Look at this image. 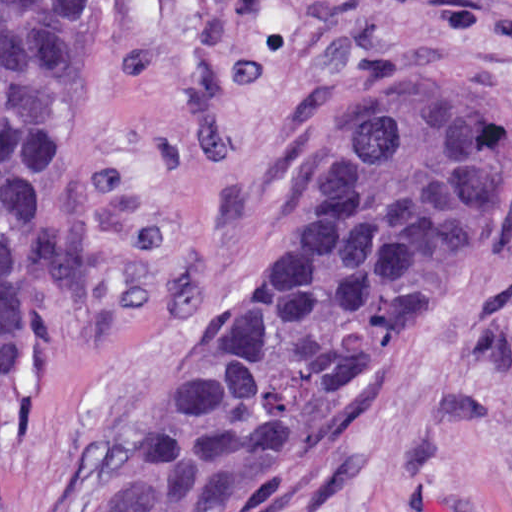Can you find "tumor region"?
Returning a JSON list of instances; mask_svg holds the SVG:
<instances>
[{"label":"tumor region","mask_w":512,"mask_h":512,"mask_svg":"<svg viewBox=\"0 0 512 512\" xmlns=\"http://www.w3.org/2000/svg\"><path fill=\"white\" fill-rule=\"evenodd\" d=\"M83 1H1V430L64 241ZM512 219V97L417 61L339 100L271 277L80 512H284L321 480Z\"/></svg>","instance_id":"obj_1"}]
</instances>
